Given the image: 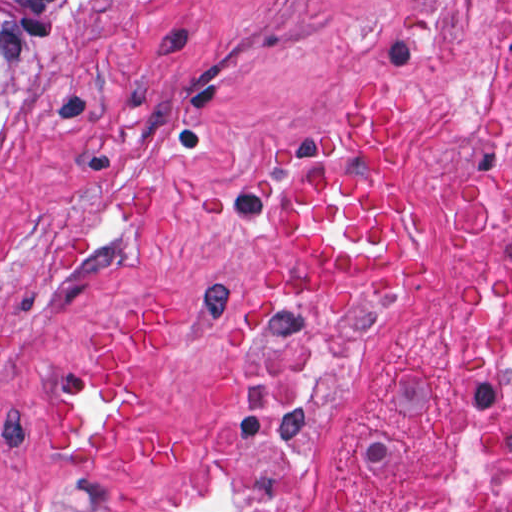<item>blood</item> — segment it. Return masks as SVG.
Returning <instances> with one entry per match:
<instances>
[{
	"label": "blood",
	"mask_w": 512,
	"mask_h": 512,
	"mask_svg": "<svg viewBox=\"0 0 512 512\" xmlns=\"http://www.w3.org/2000/svg\"><path fill=\"white\" fill-rule=\"evenodd\" d=\"M407 116V95L360 81L342 92L338 133L286 143V249L294 267L328 280V291L408 292L424 271L431 195L394 152ZM171 331L172 307L158 297L135 301L53 401L52 427L80 448H132L190 467L194 431L150 395V357Z\"/></svg>",
	"instance_id": "1a1defca"
}]
</instances>
